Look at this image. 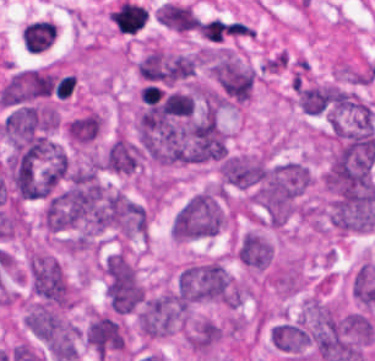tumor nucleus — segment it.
<instances>
[{
  "mask_svg": "<svg viewBox=\"0 0 375 361\" xmlns=\"http://www.w3.org/2000/svg\"><path fill=\"white\" fill-rule=\"evenodd\" d=\"M313 182L311 168L299 160L270 162L250 201L266 225L278 228L303 216Z\"/></svg>",
  "mask_w": 375,
  "mask_h": 361,
  "instance_id": "2f306a5c",
  "label": "tumor nucleus"
},
{
  "mask_svg": "<svg viewBox=\"0 0 375 361\" xmlns=\"http://www.w3.org/2000/svg\"><path fill=\"white\" fill-rule=\"evenodd\" d=\"M227 218L225 192L209 186L197 191L179 208L171 231L176 239L215 236L223 230Z\"/></svg>",
  "mask_w": 375,
  "mask_h": 361,
  "instance_id": "8643909e",
  "label": "tumor nucleus"
},
{
  "mask_svg": "<svg viewBox=\"0 0 375 361\" xmlns=\"http://www.w3.org/2000/svg\"><path fill=\"white\" fill-rule=\"evenodd\" d=\"M180 295L191 301L233 305L234 281L222 259L211 258L191 262L176 278Z\"/></svg>",
  "mask_w": 375,
  "mask_h": 361,
  "instance_id": "5ab6c2c4",
  "label": "tumor nucleus"
},
{
  "mask_svg": "<svg viewBox=\"0 0 375 361\" xmlns=\"http://www.w3.org/2000/svg\"><path fill=\"white\" fill-rule=\"evenodd\" d=\"M27 273L31 294L40 302L63 309L74 303V286L50 252L33 248L27 260Z\"/></svg>",
  "mask_w": 375,
  "mask_h": 361,
  "instance_id": "2cbd58db",
  "label": "tumor nucleus"
},
{
  "mask_svg": "<svg viewBox=\"0 0 375 361\" xmlns=\"http://www.w3.org/2000/svg\"><path fill=\"white\" fill-rule=\"evenodd\" d=\"M27 325L57 361H68L77 355L79 330L61 312L42 304L27 311Z\"/></svg>",
  "mask_w": 375,
  "mask_h": 361,
  "instance_id": "3d1891a8",
  "label": "tumor nucleus"
},
{
  "mask_svg": "<svg viewBox=\"0 0 375 361\" xmlns=\"http://www.w3.org/2000/svg\"><path fill=\"white\" fill-rule=\"evenodd\" d=\"M185 305L175 289L144 296L138 305V321L143 335L160 338L174 332L182 323Z\"/></svg>",
  "mask_w": 375,
  "mask_h": 361,
  "instance_id": "2083b535",
  "label": "tumor nucleus"
},
{
  "mask_svg": "<svg viewBox=\"0 0 375 361\" xmlns=\"http://www.w3.org/2000/svg\"><path fill=\"white\" fill-rule=\"evenodd\" d=\"M212 74L227 98L238 103L252 98L256 73L236 54L221 53L213 59Z\"/></svg>",
  "mask_w": 375,
  "mask_h": 361,
  "instance_id": "8087334f",
  "label": "tumor nucleus"
},
{
  "mask_svg": "<svg viewBox=\"0 0 375 361\" xmlns=\"http://www.w3.org/2000/svg\"><path fill=\"white\" fill-rule=\"evenodd\" d=\"M103 281L109 309L131 313L138 303L122 251L110 253L104 259Z\"/></svg>",
  "mask_w": 375,
  "mask_h": 361,
  "instance_id": "c2bd9aea",
  "label": "tumor nucleus"
},
{
  "mask_svg": "<svg viewBox=\"0 0 375 361\" xmlns=\"http://www.w3.org/2000/svg\"><path fill=\"white\" fill-rule=\"evenodd\" d=\"M219 171L224 187L252 192L267 172V161L258 154L229 153Z\"/></svg>",
  "mask_w": 375,
  "mask_h": 361,
  "instance_id": "feef74b5",
  "label": "tumor nucleus"
},
{
  "mask_svg": "<svg viewBox=\"0 0 375 361\" xmlns=\"http://www.w3.org/2000/svg\"><path fill=\"white\" fill-rule=\"evenodd\" d=\"M89 345L101 354L122 348L125 339L118 321L101 313H91L85 332Z\"/></svg>",
  "mask_w": 375,
  "mask_h": 361,
  "instance_id": "3e47fb67",
  "label": "tumor nucleus"
},
{
  "mask_svg": "<svg viewBox=\"0 0 375 361\" xmlns=\"http://www.w3.org/2000/svg\"><path fill=\"white\" fill-rule=\"evenodd\" d=\"M143 165V157L138 147L129 139L118 136L104 153L100 167L103 171L133 174Z\"/></svg>",
  "mask_w": 375,
  "mask_h": 361,
  "instance_id": "f7901128",
  "label": "tumor nucleus"
},
{
  "mask_svg": "<svg viewBox=\"0 0 375 361\" xmlns=\"http://www.w3.org/2000/svg\"><path fill=\"white\" fill-rule=\"evenodd\" d=\"M223 328L210 318H197L186 331L191 349L207 353L221 338Z\"/></svg>",
  "mask_w": 375,
  "mask_h": 361,
  "instance_id": "268c6acd",
  "label": "tumor nucleus"
},
{
  "mask_svg": "<svg viewBox=\"0 0 375 361\" xmlns=\"http://www.w3.org/2000/svg\"><path fill=\"white\" fill-rule=\"evenodd\" d=\"M331 86L328 84H313L299 89L298 103L304 112L320 114L330 103Z\"/></svg>",
  "mask_w": 375,
  "mask_h": 361,
  "instance_id": "1edb0cf7",
  "label": "tumor nucleus"
},
{
  "mask_svg": "<svg viewBox=\"0 0 375 361\" xmlns=\"http://www.w3.org/2000/svg\"><path fill=\"white\" fill-rule=\"evenodd\" d=\"M103 124V116L99 111H87L78 116L72 144L78 146L93 145Z\"/></svg>",
  "mask_w": 375,
  "mask_h": 361,
  "instance_id": "962dda3e",
  "label": "tumor nucleus"
}]
</instances>
